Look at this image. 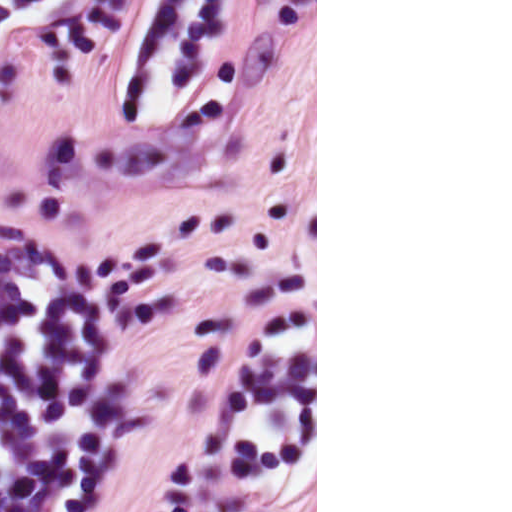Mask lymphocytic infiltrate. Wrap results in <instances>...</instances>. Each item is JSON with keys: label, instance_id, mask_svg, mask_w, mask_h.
Returning <instances> with one entry per match:
<instances>
[{"label": "lymphocytic infiltrate", "instance_id": "f902f5d3", "mask_svg": "<svg viewBox=\"0 0 512 512\" xmlns=\"http://www.w3.org/2000/svg\"><path fill=\"white\" fill-rule=\"evenodd\" d=\"M108 501L0 250V512H95Z\"/></svg>", "mask_w": 512, "mask_h": 512}]
</instances>
